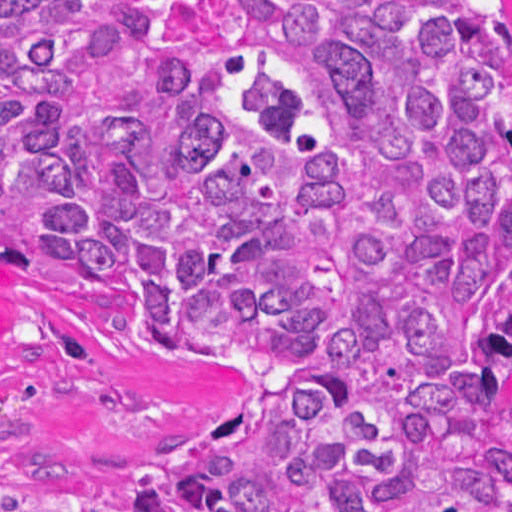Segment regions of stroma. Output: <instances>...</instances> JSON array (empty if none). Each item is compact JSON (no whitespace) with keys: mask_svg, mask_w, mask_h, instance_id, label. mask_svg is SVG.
Masks as SVG:
<instances>
[{"mask_svg":"<svg viewBox=\"0 0 512 512\" xmlns=\"http://www.w3.org/2000/svg\"><path fill=\"white\" fill-rule=\"evenodd\" d=\"M261 387L141 368L56 288L0 265V488L38 512H146V470L265 408Z\"/></svg>","mask_w":512,"mask_h":512,"instance_id":"1","label":"stroma"}]
</instances>
